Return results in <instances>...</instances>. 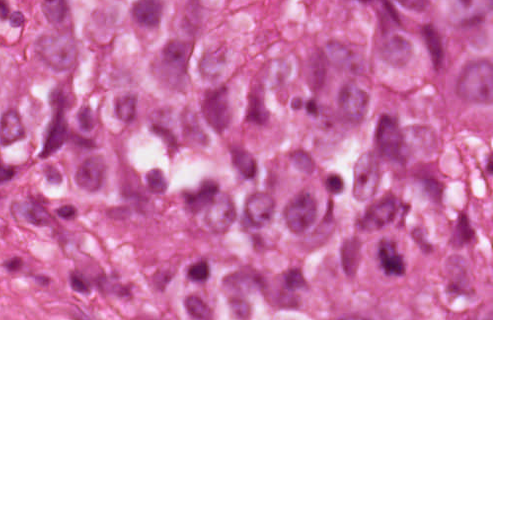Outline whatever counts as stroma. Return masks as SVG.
Masks as SVG:
<instances>
[{"mask_svg": "<svg viewBox=\"0 0 512 512\" xmlns=\"http://www.w3.org/2000/svg\"><path fill=\"white\" fill-rule=\"evenodd\" d=\"M492 319H0V320H493V0H491Z\"/></svg>", "mask_w": 512, "mask_h": 512, "instance_id": "obj_1", "label": "stroma"}]
</instances>
